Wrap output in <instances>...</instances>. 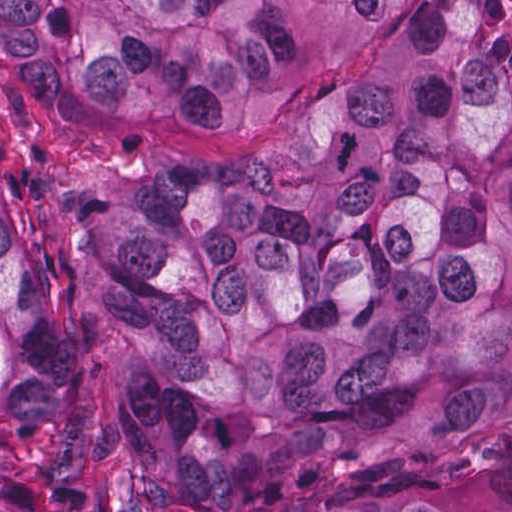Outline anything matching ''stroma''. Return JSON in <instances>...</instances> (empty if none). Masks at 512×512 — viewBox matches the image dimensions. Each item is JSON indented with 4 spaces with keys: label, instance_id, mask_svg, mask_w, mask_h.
Here are the masks:
<instances>
[{
    "label": "stroma",
    "instance_id": "35a3bbf8",
    "mask_svg": "<svg viewBox=\"0 0 512 512\" xmlns=\"http://www.w3.org/2000/svg\"><path fill=\"white\" fill-rule=\"evenodd\" d=\"M1 1H495V0H0V512L1 163L33 239L36 297L58 326L70 393L98 436L80 464L64 512H128L131 444L121 399L125 340L95 300L86 261L67 234L47 178L59 168L217 165L292 138L352 96L366 61H335L301 98L264 122L74 121L34 98L1 61Z\"/></svg>",
    "mask_w": 512,
    "mask_h": 512
}]
</instances>
